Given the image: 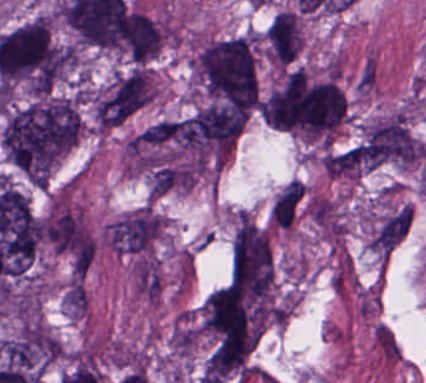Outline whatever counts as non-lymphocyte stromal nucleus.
Returning a JSON list of instances; mask_svg holds the SVG:
<instances>
[{
  "mask_svg": "<svg viewBox=\"0 0 426 383\" xmlns=\"http://www.w3.org/2000/svg\"><path fill=\"white\" fill-rule=\"evenodd\" d=\"M65 307L72 317L83 316L87 308V290L81 276H73L64 289Z\"/></svg>",
  "mask_w": 426,
  "mask_h": 383,
  "instance_id": "non-lymphocyte-stromal-nucleus-1",
  "label": "non-lymphocyte stromal nucleus"
}]
</instances>
